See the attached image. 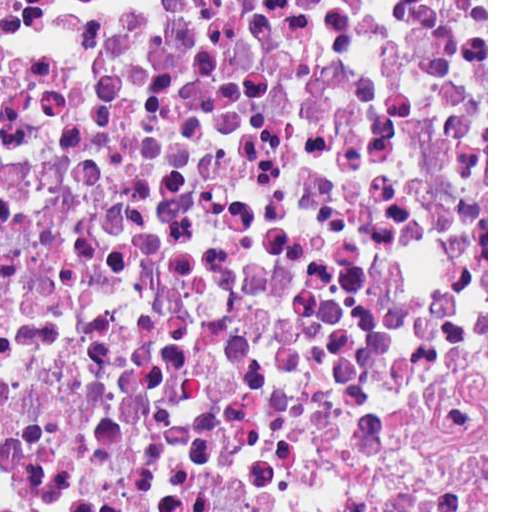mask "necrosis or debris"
<instances>
[{"instance_id":"4bbe7bcc","label":"necrosis or debris","mask_w":512,"mask_h":512,"mask_svg":"<svg viewBox=\"0 0 512 512\" xmlns=\"http://www.w3.org/2000/svg\"><path fill=\"white\" fill-rule=\"evenodd\" d=\"M487 0L0 1V512H486Z\"/></svg>"}]
</instances>
